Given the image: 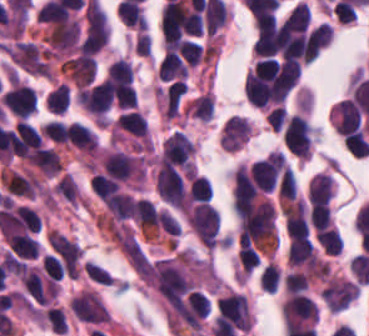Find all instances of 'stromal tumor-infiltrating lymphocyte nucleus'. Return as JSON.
<instances>
[{"mask_svg": "<svg viewBox=\"0 0 369 336\" xmlns=\"http://www.w3.org/2000/svg\"><path fill=\"white\" fill-rule=\"evenodd\" d=\"M281 271L278 265L267 263L264 265L259 277L258 285L266 291L275 292L280 280Z\"/></svg>", "mask_w": 369, "mask_h": 336, "instance_id": "15", "label": "stromal tumor-infiltrating lymphocyte nucleus"}, {"mask_svg": "<svg viewBox=\"0 0 369 336\" xmlns=\"http://www.w3.org/2000/svg\"><path fill=\"white\" fill-rule=\"evenodd\" d=\"M69 86L63 81L52 88L45 100L48 111L55 114H64L69 98Z\"/></svg>", "mask_w": 369, "mask_h": 336, "instance_id": "10", "label": "stromal tumor-infiltrating lymphocyte nucleus"}, {"mask_svg": "<svg viewBox=\"0 0 369 336\" xmlns=\"http://www.w3.org/2000/svg\"><path fill=\"white\" fill-rule=\"evenodd\" d=\"M189 115L200 121H208L214 110V97L210 91H203L187 106Z\"/></svg>", "mask_w": 369, "mask_h": 336, "instance_id": "9", "label": "stromal tumor-infiltrating lymphocyte nucleus"}, {"mask_svg": "<svg viewBox=\"0 0 369 336\" xmlns=\"http://www.w3.org/2000/svg\"><path fill=\"white\" fill-rule=\"evenodd\" d=\"M105 80L113 102L132 82V69L125 57H118L110 63Z\"/></svg>", "mask_w": 369, "mask_h": 336, "instance_id": "5", "label": "stromal tumor-infiltrating lymphocyte nucleus"}, {"mask_svg": "<svg viewBox=\"0 0 369 336\" xmlns=\"http://www.w3.org/2000/svg\"><path fill=\"white\" fill-rule=\"evenodd\" d=\"M65 142L86 154L99 149L96 133L82 121H63Z\"/></svg>", "mask_w": 369, "mask_h": 336, "instance_id": "3", "label": "stromal tumor-infiltrating lymphocyte nucleus"}, {"mask_svg": "<svg viewBox=\"0 0 369 336\" xmlns=\"http://www.w3.org/2000/svg\"><path fill=\"white\" fill-rule=\"evenodd\" d=\"M43 317L48 327L57 333H65L67 324L61 309L57 305H50L43 313Z\"/></svg>", "mask_w": 369, "mask_h": 336, "instance_id": "17", "label": "stromal tumor-infiltrating lymphocyte nucleus"}, {"mask_svg": "<svg viewBox=\"0 0 369 336\" xmlns=\"http://www.w3.org/2000/svg\"><path fill=\"white\" fill-rule=\"evenodd\" d=\"M333 30L324 21L316 26L306 36L303 47V62H310L332 40Z\"/></svg>", "mask_w": 369, "mask_h": 336, "instance_id": "7", "label": "stromal tumor-infiltrating lymphocyte nucleus"}, {"mask_svg": "<svg viewBox=\"0 0 369 336\" xmlns=\"http://www.w3.org/2000/svg\"><path fill=\"white\" fill-rule=\"evenodd\" d=\"M313 255L314 248L310 240L292 237L287 251V261L290 265L309 266L313 261Z\"/></svg>", "mask_w": 369, "mask_h": 336, "instance_id": "8", "label": "stromal tumor-infiltrating lymphocyte nucleus"}, {"mask_svg": "<svg viewBox=\"0 0 369 336\" xmlns=\"http://www.w3.org/2000/svg\"><path fill=\"white\" fill-rule=\"evenodd\" d=\"M282 138L285 147L299 159H308L312 151L310 128L299 114H292L283 125Z\"/></svg>", "mask_w": 369, "mask_h": 336, "instance_id": "1", "label": "stromal tumor-infiltrating lymphocyte nucleus"}, {"mask_svg": "<svg viewBox=\"0 0 369 336\" xmlns=\"http://www.w3.org/2000/svg\"><path fill=\"white\" fill-rule=\"evenodd\" d=\"M307 286V275L299 270L284 273L283 289L285 292L293 293L305 290Z\"/></svg>", "mask_w": 369, "mask_h": 336, "instance_id": "19", "label": "stromal tumor-infiltrating lymphocyte nucleus"}, {"mask_svg": "<svg viewBox=\"0 0 369 336\" xmlns=\"http://www.w3.org/2000/svg\"><path fill=\"white\" fill-rule=\"evenodd\" d=\"M188 193L192 201H209L211 197L209 179L205 175H192L189 178Z\"/></svg>", "mask_w": 369, "mask_h": 336, "instance_id": "12", "label": "stromal tumor-infiltrating lymphocyte nucleus"}, {"mask_svg": "<svg viewBox=\"0 0 369 336\" xmlns=\"http://www.w3.org/2000/svg\"><path fill=\"white\" fill-rule=\"evenodd\" d=\"M0 98L12 114L25 119L33 113L37 106L33 88L15 79L0 94Z\"/></svg>", "mask_w": 369, "mask_h": 336, "instance_id": "2", "label": "stromal tumor-infiltrating lymphocyte nucleus"}, {"mask_svg": "<svg viewBox=\"0 0 369 336\" xmlns=\"http://www.w3.org/2000/svg\"><path fill=\"white\" fill-rule=\"evenodd\" d=\"M114 106L127 109L136 102V90L131 83H119L113 93Z\"/></svg>", "mask_w": 369, "mask_h": 336, "instance_id": "16", "label": "stromal tumor-infiltrating lymphocyte nucleus"}, {"mask_svg": "<svg viewBox=\"0 0 369 336\" xmlns=\"http://www.w3.org/2000/svg\"><path fill=\"white\" fill-rule=\"evenodd\" d=\"M342 141L344 147L353 155L363 157L369 151V141L358 128L344 134Z\"/></svg>", "mask_w": 369, "mask_h": 336, "instance_id": "11", "label": "stromal tumor-infiltrating lymphocyte nucleus"}, {"mask_svg": "<svg viewBox=\"0 0 369 336\" xmlns=\"http://www.w3.org/2000/svg\"><path fill=\"white\" fill-rule=\"evenodd\" d=\"M83 267L90 280L100 284H114V280L106 272L102 265H99L91 260H84Z\"/></svg>", "mask_w": 369, "mask_h": 336, "instance_id": "21", "label": "stromal tumor-infiltrating lymphocyte nucleus"}, {"mask_svg": "<svg viewBox=\"0 0 369 336\" xmlns=\"http://www.w3.org/2000/svg\"><path fill=\"white\" fill-rule=\"evenodd\" d=\"M44 136L51 140L65 141V126L57 119H50L43 124Z\"/></svg>", "mask_w": 369, "mask_h": 336, "instance_id": "23", "label": "stromal tumor-infiltrating lymphocyte nucleus"}, {"mask_svg": "<svg viewBox=\"0 0 369 336\" xmlns=\"http://www.w3.org/2000/svg\"><path fill=\"white\" fill-rule=\"evenodd\" d=\"M189 66L180 52L168 51L161 56L155 75L160 80L180 79L188 75Z\"/></svg>", "mask_w": 369, "mask_h": 336, "instance_id": "6", "label": "stromal tumor-infiltrating lymphocyte nucleus"}, {"mask_svg": "<svg viewBox=\"0 0 369 336\" xmlns=\"http://www.w3.org/2000/svg\"><path fill=\"white\" fill-rule=\"evenodd\" d=\"M237 259L243 271L251 272L259 264L258 254L248 245L241 244L238 247Z\"/></svg>", "mask_w": 369, "mask_h": 336, "instance_id": "20", "label": "stromal tumor-infiltrating lymphocyte nucleus"}, {"mask_svg": "<svg viewBox=\"0 0 369 336\" xmlns=\"http://www.w3.org/2000/svg\"><path fill=\"white\" fill-rule=\"evenodd\" d=\"M251 125L243 116L230 115L225 119L219 139L220 147L239 149L249 138Z\"/></svg>", "mask_w": 369, "mask_h": 336, "instance_id": "4", "label": "stromal tumor-infiltrating lymphocyte nucleus"}, {"mask_svg": "<svg viewBox=\"0 0 369 336\" xmlns=\"http://www.w3.org/2000/svg\"><path fill=\"white\" fill-rule=\"evenodd\" d=\"M316 239L323 252L328 255H339L343 241L337 228L331 225Z\"/></svg>", "mask_w": 369, "mask_h": 336, "instance_id": "14", "label": "stromal tumor-infiltrating lymphocyte nucleus"}, {"mask_svg": "<svg viewBox=\"0 0 369 336\" xmlns=\"http://www.w3.org/2000/svg\"><path fill=\"white\" fill-rule=\"evenodd\" d=\"M159 228L171 241L179 235V225L176 219L165 209H158L156 212Z\"/></svg>", "mask_w": 369, "mask_h": 336, "instance_id": "18", "label": "stromal tumor-infiltrating lymphocyte nucleus"}, {"mask_svg": "<svg viewBox=\"0 0 369 336\" xmlns=\"http://www.w3.org/2000/svg\"><path fill=\"white\" fill-rule=\"evenodd\" d=\"M297 193L294 173L290 166L284 164L277 187L278 199L290 200Z\"/></svg>", "mask_w": 369, "mask_h": 336, "instance_id": "13", "label": "stromal tumor-infiltrating lymphocyte nucleus"}, {"mask_svg": "<svg viewBox=\"0 0 369 336\" xmlns=\"http://www.w3.org/2000/svg\"><path fill=\"white\" fill-rule=\"evenodd\" d=\"M286 116L285 109L281 105H274L265 114L264 120L270 129L279 130Z\"/></svg>", "mask_w": 369, "mask_h": 336, "instance_id": "22", "label": "stromal tumor-infiltrating lymphocyte nucleus"}]
</instances>
